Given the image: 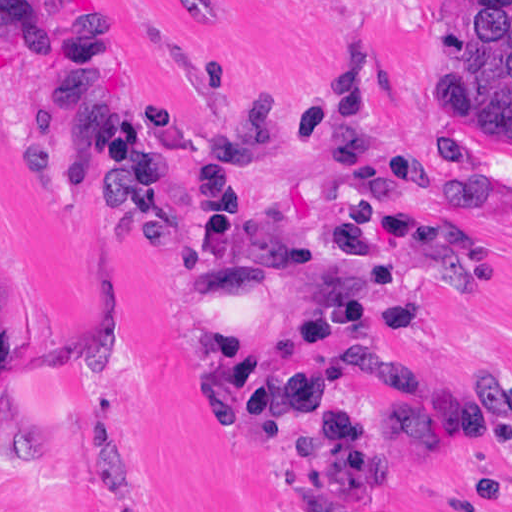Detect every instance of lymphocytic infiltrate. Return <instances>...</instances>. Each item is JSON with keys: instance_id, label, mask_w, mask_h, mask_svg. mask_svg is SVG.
I'll list each match as a JSON object with an SVG mask.
<instances>
[{"instance_id": "lymphocytic-infiltrate-1", "label": "lymphocytic infiltrate", "mask_w": 512, "mask_h": 512, "mask_svg": "<svg viewBox=\"0 0 512 512\" xmlns=\"http://www.w3.org/2000/svg\"><path fill=\"white\" fill-rule=\"evenodd\" d=\"M5 41L63 100L67 126L105 198L146 233L170 225L176 174H191L188 255L199 281L232 292L258 281L281 294L279 337L222 335L228 436L264 431L277 498L304 512H390L396 447L455 441L512 462V377L471 397L403 368L379 379L396 409L363 416L338 382L297 356L430 338L436 294L471 264V235L430 196L419 163L378 152L367 84L384 62L342 70L310 119L327 158L306 198H270L256 168L278 151L270 103L217 124L187 121L173 101L145 110L126 97L101 21L53 0H1Z\"/></svg>"}]
</instances>
